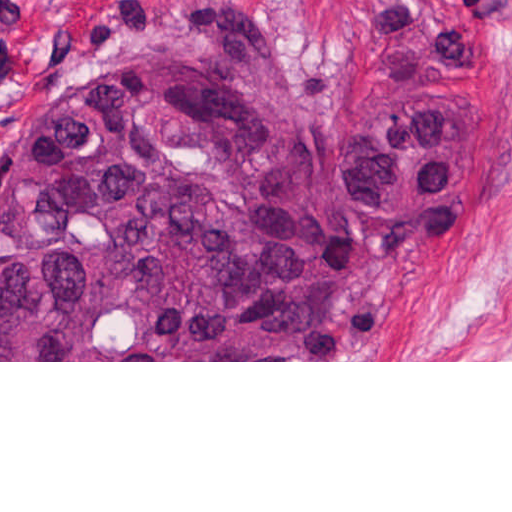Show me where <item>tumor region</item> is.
Wrapping results in <instances>:
<instances>
[{
	"label": "tumor region",
	"mask_w": 512,
	"mask_h": 512,
	"mask_svg": "<svg viewBox=\"0 0 512 512\" xmlns=\"http://www.w3.org/2000/svg\"><path fill=\"white\" fill-rule=\"evenodd\" d=\"M498 40L481 0H382L352 112L316 123L269 41L195 1L158 68L0 159V360L297 350L372 243L343 185L440 223L509 147L483 88Z\"/></svg>",
	"instance_id": "1"
}]
</instances>
